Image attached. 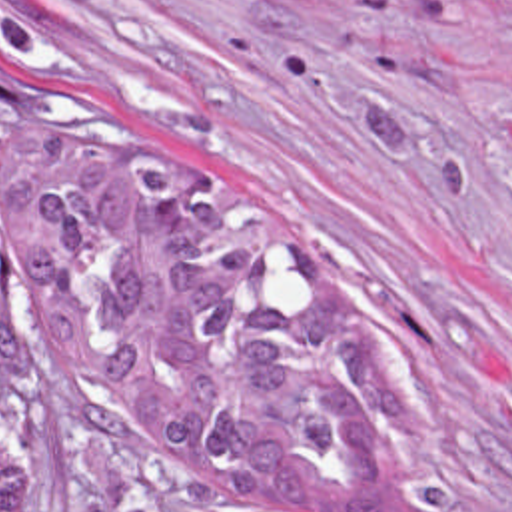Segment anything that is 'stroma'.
I'll return each mask as SVG.
<instances>
[{"label": "stroma", "instance_id": "stroma-1", "mask_svg": "<svg viewBox=\"0 0 512 512\" xmlns=\"http://www.w3.org/2000/svg\"><path fill=\"white\" fill-rule=\"evenodd\" d=\"M39 78L233 180L375 348L389 512H512V0H0ZM0 396L39 512H229L67 404L27 332Z\"/></svg>", "mask_w": 512, "mask_h": 512}]
</instances>
